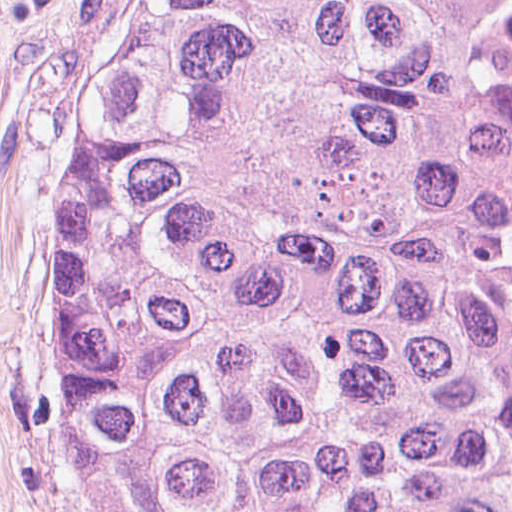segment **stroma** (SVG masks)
<instances>
[{
    "label": "stroma",
    "instance_id": "obj_1",
    "mask_svg": "<svg viewBox=\"0 0 512 512\" xmlns=\"http://www.w3.org/2000/svg\"><path fill=\"white\" fill-rule=\"evenodd\" d=\"M124 0H0V512H88L50 430V291L103 41Z\"/></svg>",
    "mask_w": 512,
    "mask_h": 512
}]
</instances>
